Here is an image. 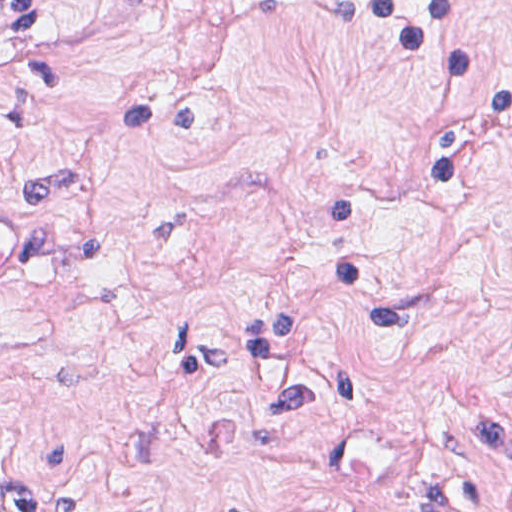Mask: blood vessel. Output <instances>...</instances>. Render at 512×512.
I'll use <instances>...</instances> for the list:
<instances>
[{
	"mask_svg": "<svg viewBox=\"0 0 512 512\" xmlns=\"http://www.w3.org/2000/svg\"><path fill=\"white\" fill-rule=\"evenodd\" d=\"M38 261V226L16 204H0V293L34 282ZM312 500L283 503L268 512H329Z\"/></svg>",
	"mask_w": 512,
	"mask_h": 512,
	"instance_id": "8fb6f2fc",
	"label": "blood vessel"
}]
</instances>
